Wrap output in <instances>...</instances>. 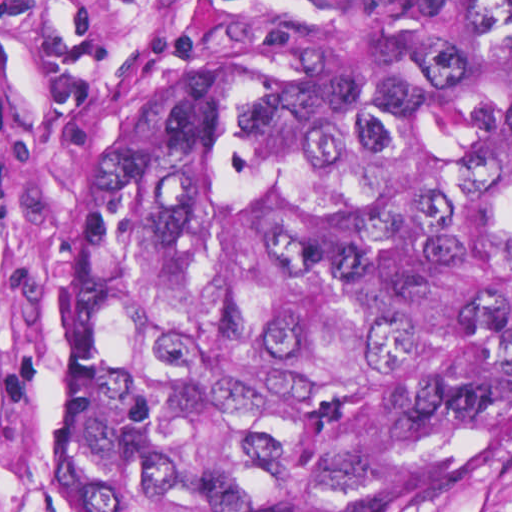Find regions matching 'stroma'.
I'll list each match as a JSON object with an SVG mask.
<instances>
[{"mask_svg": "<svg viewBox=\"0 0 512 512\" xmlns=\"http://www.w3.org/2000/svg\"><path fill=\"white\" fill-rule=\"evenodd\" d=\"M232 42L200 0H0V512H74L53 409L66 226L131 123ZM353 497L512 512V318L461 418Z\"/></svg>", "mask_w": 512, "mask_h": 512, "instance_id": "obj_1", "label": "stroma"}]
</instances>
